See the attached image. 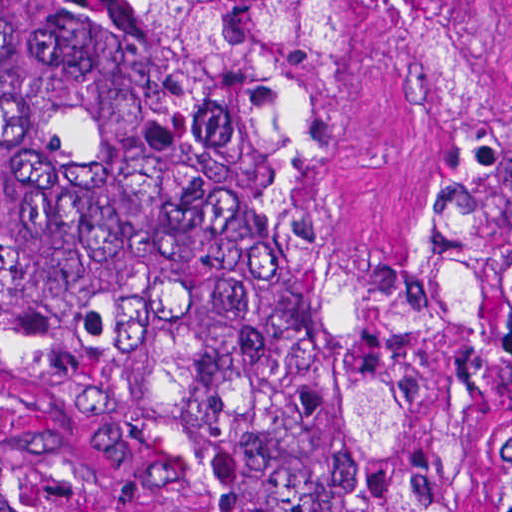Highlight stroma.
<instances>
[{
  "instance_id": "35a3bbf8",
  "label": "stroma",
  "mask_w": 512,
  "mask_h": 512,
  "mask_svg": "<svg viewBox=\"0 0 512 512\" xmlns=\"http://www.w3.org/2000/svg\"><path fill=\"white\" fill-rule=\"evenodd\" d=\"M419 1L345 48L323 99V196L361 259L405 251L477 140L512 113V0ZM448 471L496 512V455ZM0 512H211L163 461L0 401Z\"/></svg>"
}]
</instances>
